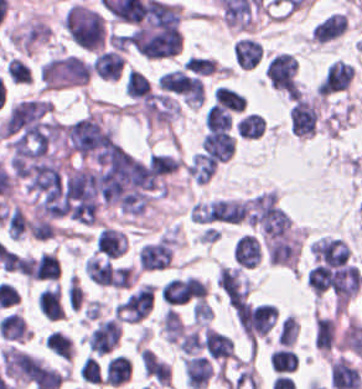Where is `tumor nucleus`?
Wrapping results in <instances>:
<instances>
[{
    "mask_svg": "<svg viewBox=\"0 0 362 389\" xmlns=\"http://www.w3.org/2000/svg\"><path fill=\"white\" fill-rule=\"evenodd\" d=\"M28 231L35 240H47L55 236L48 220L41 216H34L28 221Z\"/></svg>",
    "mask_w": 362,
    "mask_h": 389,
    "instance_id": "1",
    "label": "tumor nucleus"
}]
</instances>
